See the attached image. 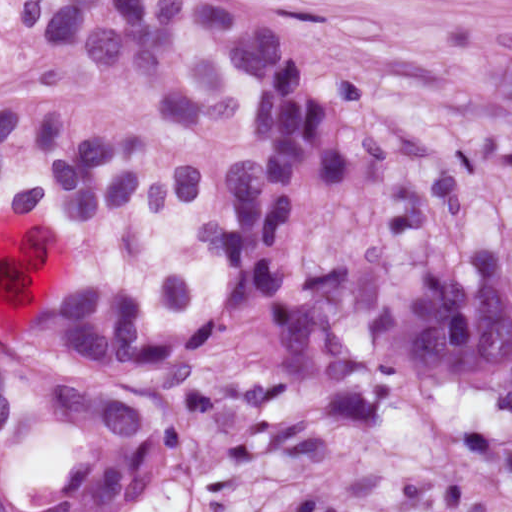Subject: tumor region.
Returning <instances> with one entry per match:
<instances>
[{"instance_id":"e687c5a6","label":"tumor region","mask_w":512,"mask_h":512,"mask_svg":"<svg viewBox=\"0 0 512 512\" xmlns=\"http://www.w3.org/2000/svg\"><path fill=\"white\" fill-rule=\"evenodd\" d=\"M512 15V0H474Z\"/></svg>"}]
</instances>
